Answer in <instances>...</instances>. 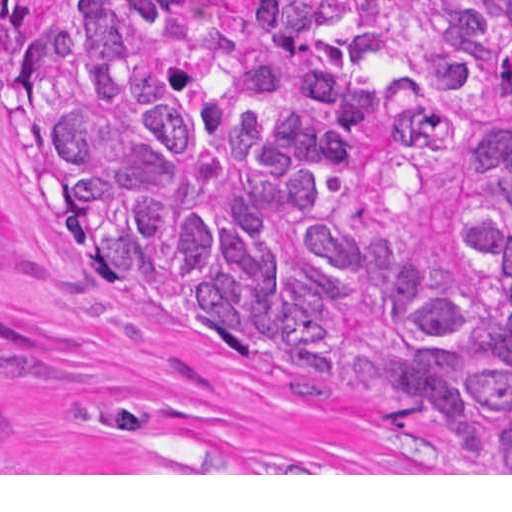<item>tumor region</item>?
<instances>
[{
	"label": "tumor region",
	"mask_w": 512,
	"mask_h": 512,
	"mask_svg": "<svg viewBox=\"0 0 512 512\" xmlns=\"http://www.w3.org/2000/svg\"><path fill=\"white\" fill-rule=\"evenodd\" d=\"M240 68L179 0H1V141L56 233L303 405L512 473V0H297Z\"/></svg>",
	"instance_id": "e687c5a6"
}]
</instances>
